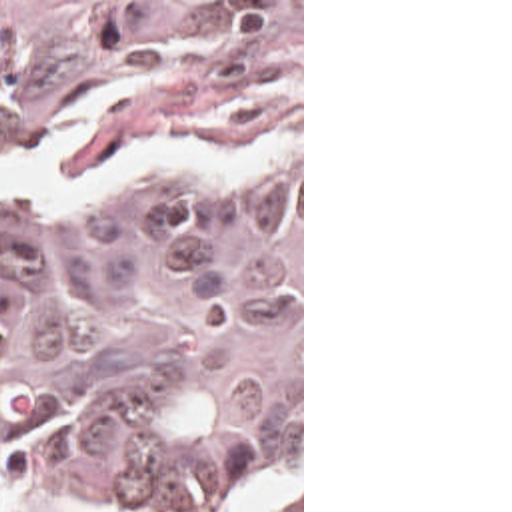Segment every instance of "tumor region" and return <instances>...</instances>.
Returning <instances> with one entry per match:
<instances>
[{
	"instance_id": "obj_1",
	"label": "tumor region",
	"mask_w": 512,
	"mask_h": 512,
	"mask_svg": "<svg viewBox=\"0 0 512 512\" xmlns=\"http://www.w3.org/2000/svg\"><path fill=\"white\" fill-rule=\"evenodd\" d=\"M68 124L56 184L142 144L270 148L244 194L0 202V495L248 512L300 373V2H0V168Z\"/></svg>"
}]
</instances>
